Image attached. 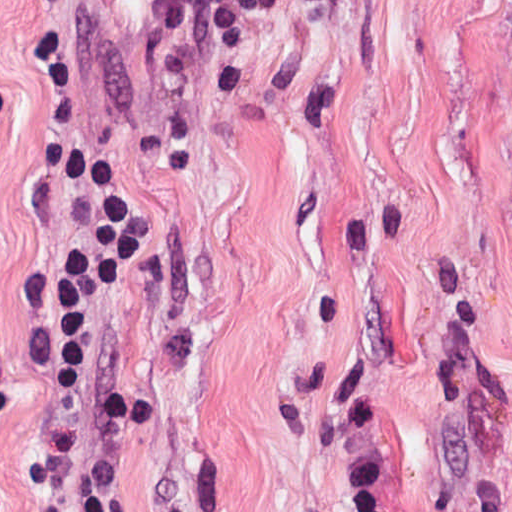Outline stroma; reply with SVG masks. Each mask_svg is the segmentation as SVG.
Masks as SVG:
<instances>
[{
	"instance_id": "stroma-1",
	"label": "stroma",
	"mask_w": 512,
	"mask_h": 512,
	"mask_svg": "<svg viewBox=\"0 0 512 512\" xmlns=\"http://www.w3.org/2000/svg\"><path fill=\"white\" fill-rule=\"evenodd\" d=\"M154 2L0 0V512H512V0L284 3L244 95L205 24L149 83ZM39 38L144 223L81 442Z\"/></svg>"
}]
</instances>
